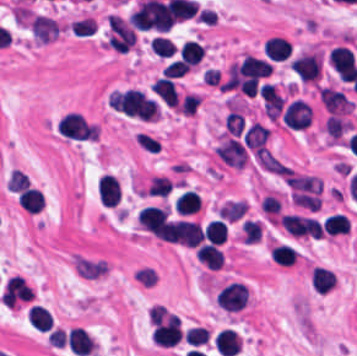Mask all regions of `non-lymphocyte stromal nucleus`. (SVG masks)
<instances>
[{
  "instance_id": "a72fc3eb",
  "label": "non-lymphocyte stromal nucleus",
  "mask_w": 357,
  "mask_h": 356,
  "mask_svg": "<svg viewBox=\"0 0 357 356\" xmlns=\"http://www.w3.org/2000/svg\"><path fill=\"white\" fill-rule=\"evenodd\" d=\"M130 275L134 283L141 288H154L158 279L156 267L146 263H139L131 270Z\"/></svg>"
},
{
  "instance_id": "dd21d789",
  "label": "non-lymphocyte stromal nucleus",
  "mask_w": 357,
  "mask_h": 356,
  "mask_svg": "<svg viewBox=\"0 0 357 356\" xmlns=\"http://www.w3.org/2000/svg\"><path fill=\"white\" fill-rule=\"evenodd\" d=\"M216 149L223 163L234 169H243L246 154L241 143L235 138L222 137Z\"/></svg>"
}]
</instances>
